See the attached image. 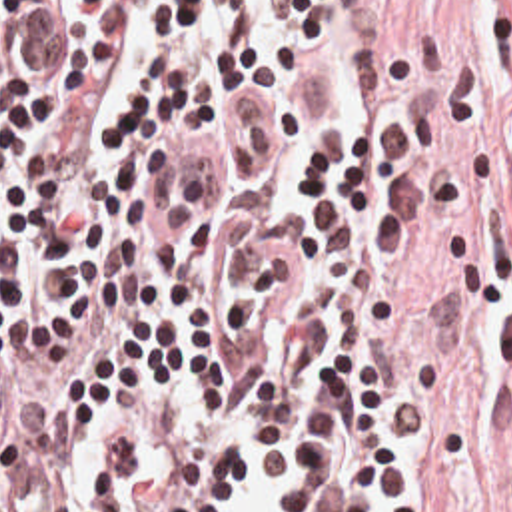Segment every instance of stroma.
I'll return each mask as SVG.
<instances>
[{"label": "stroma", "instance_id": "obj_1", "mask_svg": "<svg viewBox=\"0 0 512 512\" xmlns=\"http://www.w3.org/2000/svg\"><path fill=\"white\" fill-rule=\"evenodd\" d=\"M421 119L413 390L459 512H512V0H346Z\"/></svg>", "mask_w": 512, "mask_h": 512}]
</instances>
